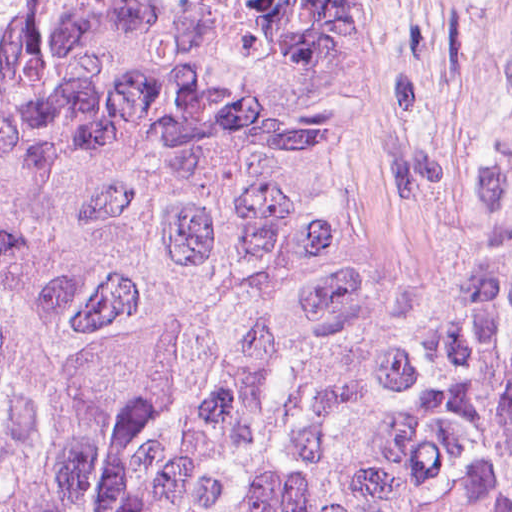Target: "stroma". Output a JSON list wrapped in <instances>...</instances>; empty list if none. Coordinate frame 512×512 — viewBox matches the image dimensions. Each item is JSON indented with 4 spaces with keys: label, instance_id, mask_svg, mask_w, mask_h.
<instances>
[{
    "label": "stroma",
    "instance_id": "35a3bbf8",
    "mask_svg": "<svg viewBox=\"0 0 512 512\" xmlns=\"http://www.w3.org/2000/svg\"><path fill=\"white\" fill-rule=\"evenodd\" d=\"M300 112L305 140L314 163L320 184L333 207L350 232L367 262L405 278L428 261H396L348 220L335 198L325 157V89L312 61L311 53L298 90Z\"/></svg>",
    "mask_w": 512,
    "mask_h": 512
}]
</instances>
